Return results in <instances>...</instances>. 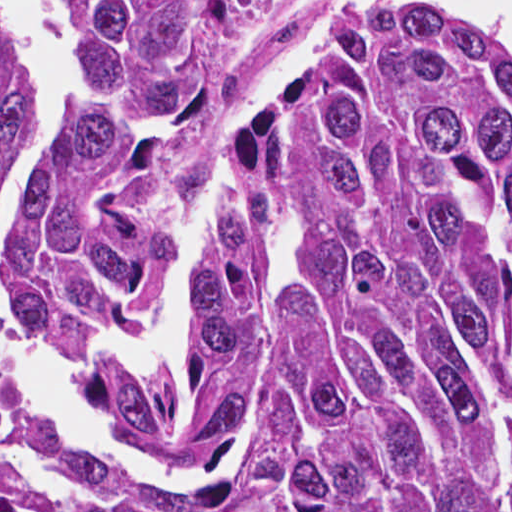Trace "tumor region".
Returning <instances> with one entry per match:
<instances>
[{"label":"tumor region","instance_id":"e687c5a6","mask_svg":"<svg viewBox=\"0 0 512 512\" xmlns=\"http://www.w3.org/2000/svg\"><path fill=\"white\" fill-rule=\"evenodd\" d=\"M274 0H49L72 84L53 177L0 284L50 344L151 323L185 177L284 220V265L214 249L161 385L90 381L87 414L190 439L249 401L222 478L122 470L0 380V512H512V34L449 4L378 18L313 98L234 147L226 90ZM10 84L0 54V174Z\"/></svg>","mask_w":512,"mask_h":512}]
</instances>
